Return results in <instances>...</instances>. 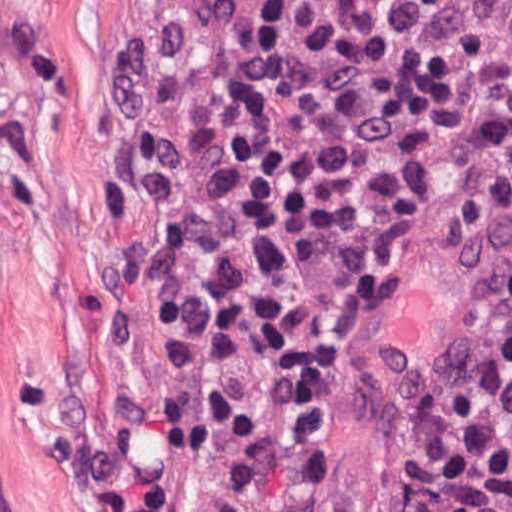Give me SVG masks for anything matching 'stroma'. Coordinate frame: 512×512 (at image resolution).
Instances as JSON below:
<instances>
[{"mask_svg":"<svg viewBox=\"0 0 512 512\" xmlns=\"http://www.w3.org/2000/svg\"><path fill=\"white\" fill-rule=\"evenodd\" d=\"M170 1L0 0V512H118L177 364L114 206L118 93ZM470 160L456 119L359 314L319 512H416L481 365L512 235L445 221Z\"/></svg>","mask_w":512,"mask_h":512,"instance_id":"1","label":"stroma"}]
</instances>
